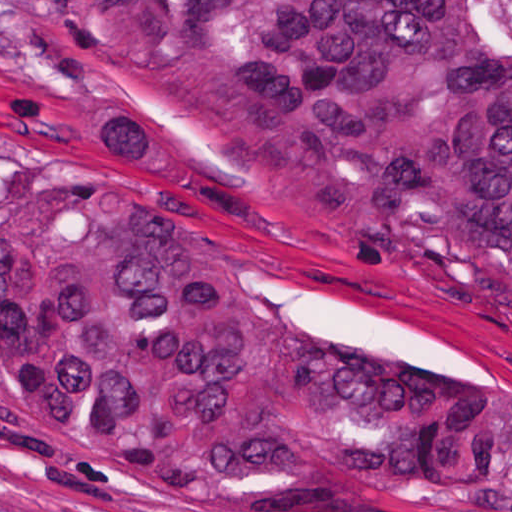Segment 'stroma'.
Wrapping results in <instances>:
<instances>
[{
  "label": "stroma",
  "instance_id": "stroma-1",
  "mask_svg": "<svg viewBox=\"0 0 512 512\" xmlns=\"http://www.w3.org/2000/svg\"><path fill=\"white\" fill-rule=\"evenodd\" d=\"M54 188L144 196L265 306L318 333L512 376V337L480 315L325 234L229 204L195 179L66 0H0V512H512V434L494 465L453 498H167L51 452L1 395V223L24 194Z\"/></svg>",
  "mask_w": 512,
  "mask_h": 512
}]
</instances>
